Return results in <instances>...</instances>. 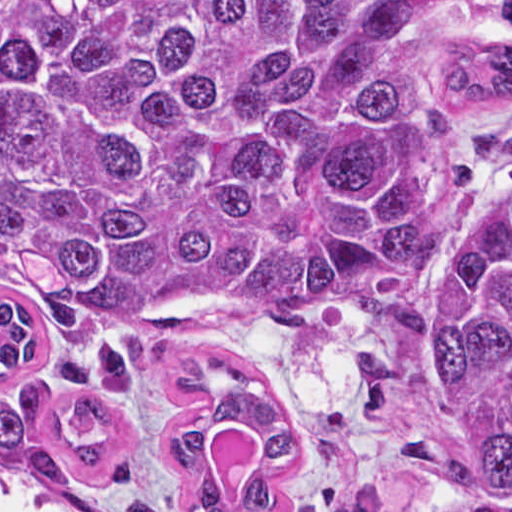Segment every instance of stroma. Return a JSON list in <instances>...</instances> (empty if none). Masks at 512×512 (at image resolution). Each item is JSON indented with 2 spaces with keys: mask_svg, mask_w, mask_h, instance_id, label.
Segmentation results:
<instances>
[{
  "mask_svg": "<svg viewBox=\"0 0 512 512\" xmlns=\"http://www.w3.org/2000/svg\"><path fill=\"white\" fill-rule=\"evenodd\" d=\"M388 12L405 2L411 10L407 65L425 111L435 78L452 43L475 36L512 49V34L493 32L501 0H375ZM512 128V98L490 100L466 112L462 130ZM512 182V161L479 172L467 207L453 217L450 249L438 269L409 292L436 312L434 337L401 374L387 397L386 411L356 419L348 403V381L362 357L388 343V306L366 318L272 320L245 314H194L174 320L150 344L146 376L138 392L103 396L122 426V454L104 474H86L70 465L71 485H35L0 469V494L53 501L75 512H130L139 500L159 512H193L197 475L211 474L222 497L239 495L267 453L268 432L249 416L217 422L210 460L188 477L173 469L163 430L176 415L200 403L206 390L173 386L175 371L201 352L253 370L277 386L291 438V463L277 480L261 512H321L315 501L327 486L349 496L374 483L386 486L376 512H438L455 486L410 467L396 474L401 443L423 436L465 462V441L448 395L439 349L441 277L498 191ZM0 301H19L38 311V353L20 370H0V392L17 398L33 380L50 387L64 416L66 432L96 442L102 430L80 419L74 399L88 390L64 375L50 352L44 313L31 293L0 261Z\"/></svg>",
  "mask_w": 512,
  "mask_h": 512,
  "instance_id": "1",
  "label": "stroma"
}]
</instances>
